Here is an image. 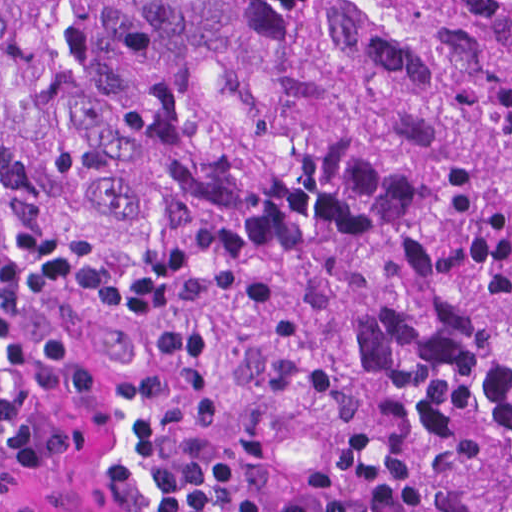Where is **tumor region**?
I'll return each mask as SVG.
<instances>
[{
  "label": "tumor region",
  "instance_id": "obj_1",
  "mask_svg": "<svg viewBox=\"0 0 512 512\" xmlns=\"http://www.w3.org/2000/svg\"><path fill=\"white\" fill-rule=\"evenodd\" d=\"M72 392L312 479L472 450L512 305V0H0Z\"/></svg>",
  "mask_w": 512,
  "mask_h": 512
}]
</instances>
